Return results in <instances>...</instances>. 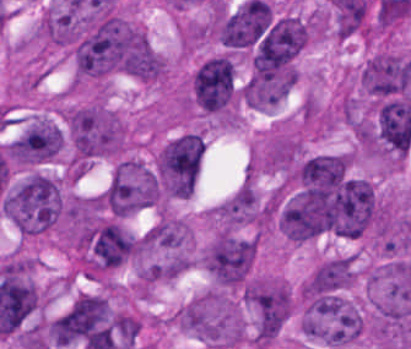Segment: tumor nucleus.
I'll return each mask as SVG.
<instances>
[{
  "mask_svg": "<svg viewBox=\"0 0 411 349\" xmlns=\"http://www.w3.org/2000/svg\"><path fill=\"white\" fill-rule=\"evenodd\" d=\"M68 165L84 166L124 152L128 126L102 99L69 103L61 107Z\"/></svg>",
  "mask_w": 411,
  "mask_h": 349,
  "instance_id": "obj_1",
  "label": "tumor nucleus"
},
{
  "mask_svg": "<svg viewBox=\"0 0 411 349\" xmlns=\"http://www.w3.org/2000/svg\"><path fill=\"white\" fill-rule=\"evenodd\" d=\"M1 210L24 237L48 232L64 212L62 182L51 173L29 169L2 191Z\"/></svg>",
  "mask_w": 411,
  "mask_h": 349,
  "instance_id": "obj_2",
  "label": "tumor nucleus"
},
{
  "mask_svg": "<svg viewBox=\"0 0 411 349\" xmlns=\"http://www.w3.org/2000/svg\"><path fill=\"white\" fill-rule=\"evenodd\" d=\"M173 317L178 329L208 347L228 349L246 342V322L230 291L207 290L181 306Z\"/></svg>",
  "mask_w": 411,
  "mask_h": 349,
  "instance_id": "obj_3",
  "label": "tumor nucleus"
},
{
  "mask_svg": "<svg viewBox=\"0 0 411 349\" xmlns=\"http://www.w3.org/2000/svg\"><path fill=\"white\" fill-rule=\"evenodd\" d=\"M299 328L321 345L350 346L363 339L368 320L341 293L322 288H303Z\"/></svg>",
  "mask_w": 411,
  "mask_h": 349,
  "instance_id": "obj_4",
  "label": "tumor nucleus"
},
{
  "mask_svg": "<svg viewBox=\"0 0 411 349\" xmlns=\"http://www.w3.org/2000/svg\"><path fill=\"white\" fill-rule=\"evenodd\" d=\"M203 159L198 131L186 130L169 137L159 149L154 168L161 190L168 197L192 195Z\"/></svg>",
  "mask_w": 411,
  "mask_h": 349,
  "instance_id": "obj_5",
  "label": "tumor nucleus"
},
{
  "mask_svg": "<svg viewBox=\"0 0 411 349\" xmlns=\"http://www.w3.org/2000/svg\"><path fill=\"white\" fill-rule=\"evenodd\" d=\"M189 91L192 109L222 119H237L241 92L225 61L209 56L192 71Z\"/></svg>",
  "mask_w": 411,
  "mask_h": 349,
  "instance_id": "obj_6",
  "label": "tumor nucleus"
},
{
  "mask_svg": "<svg viewBox=\"0 0 411 349\" xmlns=\"http://www.w3.org/2000/svg\"><path fill=\"white\" fill-rule=\"evenodd\" d=\"M252 335L274 339L293 313V292L279 275H254L245 284Z\"/></svg>",
  "mask_w": 411,
  "mask_h": 349,
  "instance_id": "obj_7",
  "label": "tumor nucleus"
},
{
  "mask_svg": "<svg viewBox=\"0 0 411 349\" xmlns=\"http://www.w3.org/2000/svg\"><path fill=\"white\" fill-rule=\"evenodd\" d=\"M101 192L115 212L134 215L155 206L156 174L134 157H121L111 166Z\"/></svg>",
  "mask_w": 411,
  "mask_h": 349,
  "instance_id": "obj_8",
  "label": "tumor nucleus"
},
{
  "mask_svg": "<svg viewBox=\"0 0 411 349\" xmlns=\"http://www.w3.org/2000/svg\"><path fill=\"white\" fill-rule=\"evenodd\" d=\"M257 247L255 237L219 231L205 249V267L218 285L241 286L251 273Z\"/></svg>",
  "mask_w": 411,
  "mask_h": 349,
  "instance_id": "obj_9",
  "label": "tumor nucleus"
},
{
  "mask_svg": "<svg viewBox=\"0 0 411 349\" xmlns=\"http://www.w3.org/2000/svg\"><path fill=\"white\" fill-rule=\"evenodd\" d=\"M63 144L62 125L48 113H35L24 121L14 141V159L23 165L57 161Z\"/></svg>",
  "mask_w": 411,
  "mask_h": 349,
  "instance_id": "obj_10",
  "label": "tumor nucleus"
},
{
  "mask_svg": "<svg viewBox=\"0 0 411 349\" xmlns=\"http://www.w3.org/2000/svg\"><path fill=\"white\" fill-rule=\"evenodd\" d=\"M219 229L255 226L264 216V200L253 180L246 178L213 209Z\"/></svg>",
  "mask_w": 411,
  "mask_h": 349,
  "instance_id": "obj_11",
  "label": "tumor nucleus"
},
{
  "mask_svg": "<svg viewBox=\"0 0 411 349\" xmlns=\"http://www.w3.org/2000/svg\"><path fill=\"white\" fill-rule=\"evenodd\" d=\"M356 275L353 255L338 254L315 265L300 284V293L344 289L354 281Z\"/></svg>",
  "mask_w": 411,
  "mask_h": 349,
  "instance_id": "obj_12",
  "label": "tumor nucleus"
},
{
  "mask_svg": "<svg viewBox=\"0 0 411 349\" xmlns=\"http://www.w3.org/2000/svg\"><path fill=\"white\" fill-rule=\"evenodd\" d=\"M191 237L190 223L163 216L141 240L149 250H177L190 247Z\"/></svg>",
  "mask_w": 411,
  "mask_h": 349,
  "instance_id": "obj_13",
  "label": "tumor nucleus"
}]
</instances>
